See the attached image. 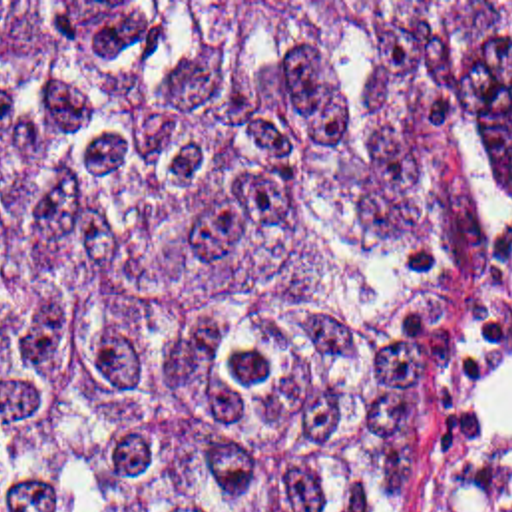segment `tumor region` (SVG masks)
Masks as SVG:
<instances>
[{"label": "tumor region", "mask_w": 512, "mask_h": 512, "mask_svg": "<svg viewBox=\"0 0 512 512\" xmlns=\"http://www.w3.org/2000/svg\"><path fill=\"white\" fill-rule=\"evenodd\" d=\"M468 177L512 18L464 84L373 2H0V512H415Z\"/></svg>", "instance_id": "e687c5a6"}]
</instances>
